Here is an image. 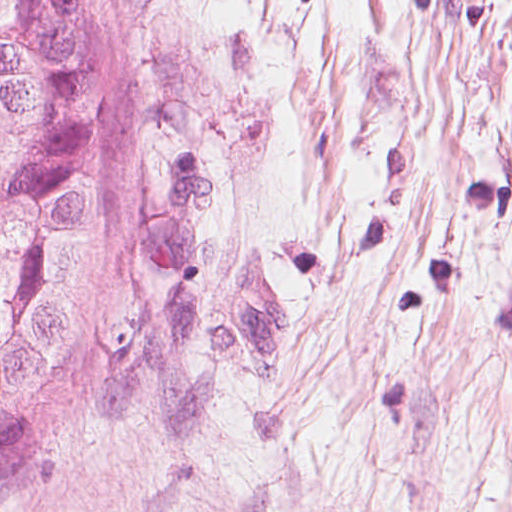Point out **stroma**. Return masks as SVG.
Segmentation results:
<instances>
[{
	"label": "stroma",
	"instance_id": "35a3bbf8",
	"mask_svg": "<svg viewBox=\"0 0 512 512\" xmlns=\"http://www.w3.org/2000/svg\"><path fill=\"white\" fill-rule=\"evenodd\" d=\"M139 223L0 512H512V0H139Z\"/></svg>",
	"mask_w": 512,
	"mask_h": 512
}]
</instances>
